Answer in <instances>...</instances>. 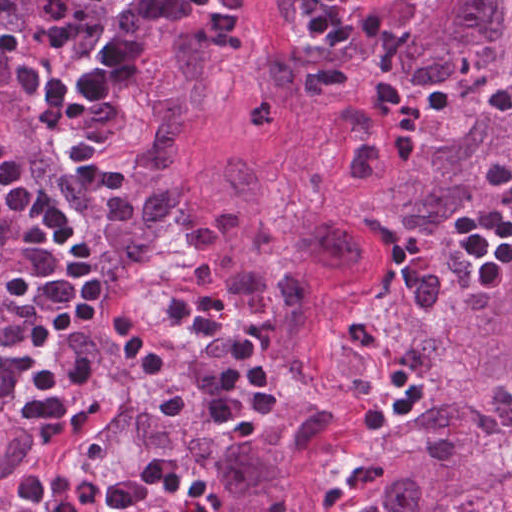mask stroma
Returning <instances> with one entry per match:
<instances>
[{
	"mask_svg": "<svg viewBox=\"0 0 512 512\" xmlns=\"http://www.w3.org/2000/svg\"><path fill=\"white\" fill-rule=\"evenodd\" d=\"M422 1L371 0L354 24L352 41L341 48L309 39L312 0H206L169 42L182 31L194 37L214 60L220 77L218 110L191 128L183 142V170L192 192L201 202L211 198L232 165L243 158L257 171L254 215L265 220L291 206L309 189L334 97L366 62L388 52ZM133 82L29 197L59 202L97 256L108 283L86 226L59 191V180L71 169L130 173L149 143V131L133 100ZM21 207L0 230L63 287L49 250L19 238ZM301 213L289 225L271 265L244 269L222 251L218 284L251 273H283ZM195 269L192 248L184 244L142 280L118 288L109 284L124 306L178 351L182 343L163 315L164 306ZM218 297L229 321L243 331ZM375 473L358 455L342 454L327 478L326 512H371L368 494Z\"/></svg>",
	"mask_w": 512,
	"mask_h": 512,
	"instance_id": "obj_1",
	"label": "stroma"
}]
</instances>
